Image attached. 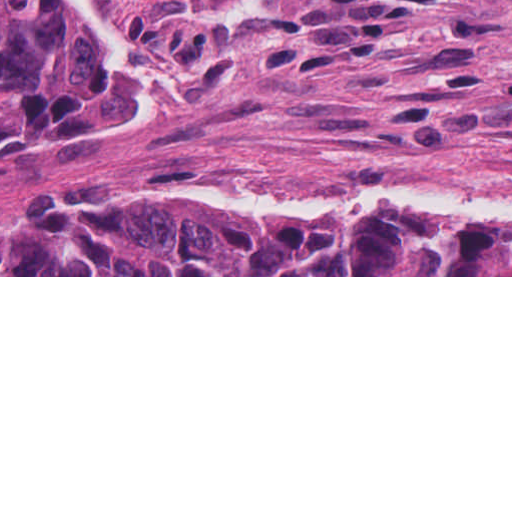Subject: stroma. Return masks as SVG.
<instances>
[{"label": "stroma", "mask_w": 512, "mask_h": 512, "mask_svg": "<svg viewBox=\"0 0 512 512\" xmlns=\"http://www.w3.org/2000/svg\"><path fill=\"white\" fill-rule=\"evenodd\" d=\"M66 5L106 109L74 150L0 167V226L186 198L326 231L391 208L512 229V0Z\"/></svg>", "instance_id": "obj_1"}]
</instances>
